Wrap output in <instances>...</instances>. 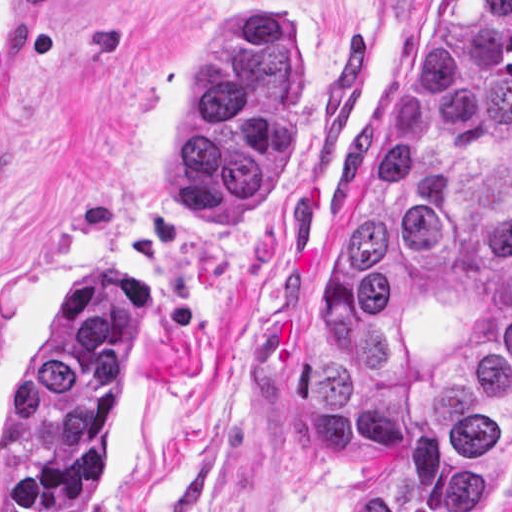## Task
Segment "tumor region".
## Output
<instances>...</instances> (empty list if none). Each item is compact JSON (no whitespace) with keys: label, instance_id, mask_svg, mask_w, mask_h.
<instances>
[{"label":"tumor region","instance_id":"e687c5a6","mask_svg":"<svg viewBox=\"0 0 512 512\" xmlns=\"http://www.w3.org/2000/svg\"><path fill=\"white\" fill-rule=\"evenodd\" d=\"M298 120L278 10L231 12L186 73L157 200L240 233L274 193ZM142 323L133 279L72 295L4 426L0 512H94ZM305 380L342 492L335 512L507 509L512 0H431L415 22L351 198L312 240Z\"/></svg>","mask_w":512,"mask_h":512}]
</instances>
